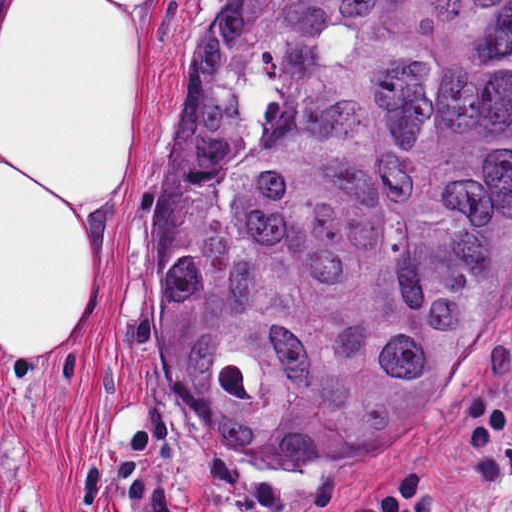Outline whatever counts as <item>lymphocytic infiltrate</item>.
<instances>
[{
	"instance_id": "f902f5d3",
	"label": "lymphocytic infiltrate",
	"mask_w": 512,
	"mask_h": 512,
	"mask_svg": "<svg viewBox=\"0 0 512 512\" xmlns=\"http://www.w3.org/2000/svg\"><path fill=\"white\" fill-rule=\"evenodd\" d=\"M468 402L469 446L500 440L506 473L512 474V417L503 420L496 398L464 396L461 411ZM459 498L453 472L418 445L397 452L377 470L358 491L351 512H452Z\"/></svg>"
}]
</instances>
